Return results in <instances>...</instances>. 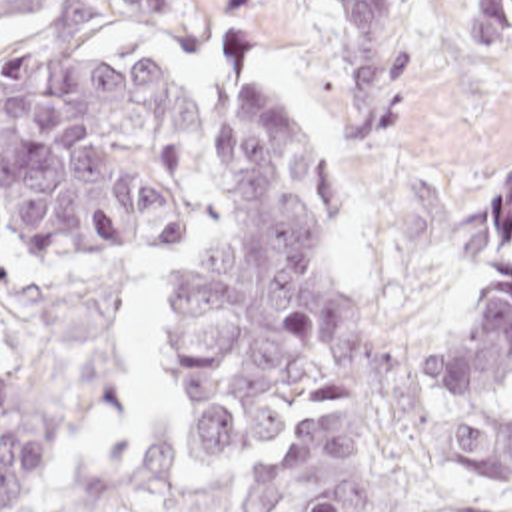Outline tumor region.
Wrapping results in <instances>:
<instances>
[{
	"label": "tumor region",
	"mask_w": 512,
	"mask_h": 512,
	"mask_svg": "<svg viewBox=\"0 0 512 512\" xmlns=\"http://www.w3.org/2000/svg\"><path fill=\"white\" fill-rule=\"evenodd\" d=\"M342 29L346 143L400 121L401 0H332ZM469 47H512V0H435ZM182 0H0V29H172ZM224 225L172 277L178 407L188 441L238 462L272 452L260 512H413L398 470L368 454L356 409L324 403L352 365L394 460L512 482V277L445 335L396 341L346 307L326 265L348 187L302 111L262 81H228L216 129ZM196 197V89L140 47H34L0 73V217L64 265H128L186 241ZM0 512L32 490L46 413L4 375Z\"/></svg>",
	"instance_id": "1"
}]
</instances>
